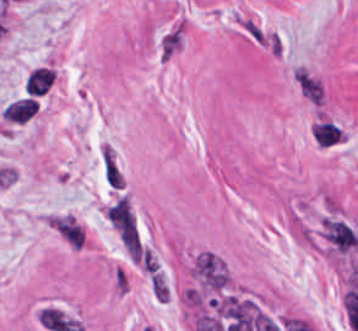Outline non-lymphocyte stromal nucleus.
Here are the masks:
<instances>
[{
    "mask_svg": "<svg viewBox=\"0 0 358 331\" xmlns=\"http://www.w3.org/2000/svg\"><path fill=\"white\" fill-rule=\"evenodd\" d=\"M193 276L205 292L222 293L228 285L223 262L212 252H199L194 259Z\"/></svg>",
    "mask_w": 358,
    "mask_h": 331,
    "instance_id": "dd21d789",
    "label": "non-lymphocyte stromal nucleus"
},
{
    "mask_svg": "<svg viewBox=\"0 0 358 331\" xmlns=\"http://www.w3.org/2000/svg\"><path fill=\"white\" fill-rule=\"evenodd\" d=\"M99 171L108 190H121L124 177L113 148L108 143H101L98 152Z\"/></svg>",
    "mask_w": 358,
    "mask_h": 331,
    "instance_id": "a72fc3eb",
    "label": "non-lymphocyte stromal nucleus"
},
{
    "mask_svg": "<svg viewBox=\"0 0 358 331\" xmlns=\"http://www.w3.org/2000/svg\"><path fill=\"white\" fill-rule=\"evenodd\" d=\"M55 80V74L49 66L38 65L31 68L25 78L24 96H44L51 88Z\"/></svg>",
    "mask_w": 358,
    "mask_h": 331,
    "instance_id": "3746e769",
    "label": "non-lymphocyte stromal nucleus"
},
{
    "mask_svg": "<svg viewBox=\"0 0 358 331\" xmlns=\"http://www.w3.org/2000/svg\"><path fill=\"white\" fill-rule=\"evenodd\" d=\"M184 41L183 24L174 23L158 39L156 44L157 58L169 61L182 48Z\"/></svg>",
    "mask_w": 358,
    "mask_h": 331,
    "instance_id": "fc2b8d12",
    "label": "non-lymphocyte stromal nucleus"
},
{
    "mask_svg": "<svg viewBox=\"0 0 358 331\" xmlns=\"http://www.w3.org/2000/svg\"><path fill=\"white\" fill-rule=\"evenodd\" d=\"M37 111V103L30 96H23L6 104L0 112V117L12 123H24Z\"/></svg>",
    "mask_w": 358,
    "mask_h": 331,
    "instance_id": "81446118",
    "label": "non-lymphocyte stromal nucleus"
},
{
    "mask_svg": "<svg viewBox=\"0 0 358 331\" xmlns=\"http://www.w3.org/2000/svg\"><path fill=\"white\" fill-rule=\"evenodd\" d=\"M49 223L66 244L80 249L82 229L71 214H58L50 218Z\"/></svg>",
    "mask_w": 358,
    "mask_h": 331,
    "instance_id": "7c5642bf",
    "label": "non-lymphocyte stromal nucleus"
},
{
    "mask_svg": "<svg viewBox=\"0 0 358 331\" xmlns=\"http://www.w3.org/2000/svg\"><path fill=\"white\" fill-rule=\"evenodd\" d=\"M312 134L318 147H328L342 136L331 121H318L312 127Z\"/></svg>",
    "mask_w": 358,
    "mask_h": 331,
    "instance_id": "9d01c50a",
    "label": "non-lymphocyte stromal nucleus"
},
{
    "mask_svg": "<svg viewBox=\"0 0 358 331\" xmlns=\"http://www.w3.org/2000/svg\"><path fill=\"white\" fill-rule=\"evenodd\" d=\"M295 80L303 95L319 104V83L303 69H296Z\"/></svg>",
    "mask_w": 358,
    "mask_h": 331,
    "instance_id": "2ac0efb1",
    "label": "non-lymphocyte stromal nucleus"
},
{
    "mask_svg": "<svg viewBox=\"0 0 358 331\" xmlns=\"http://www.w3.org/2000/svg\"><path fill=\"white\" fill-rule=\"evenodd\" d=\"M237 21L241 27V29L252 39L255 41L262 43L265 45V34L260 24L256 22L249 15L241 18H237Z\"/></svg>",
    "mask_w": 358,
    "mask_h": 331,
    "instance_id": "616ff342",
    "label": "non-lymphocyte stromal nucleus"
}]
</instances>
